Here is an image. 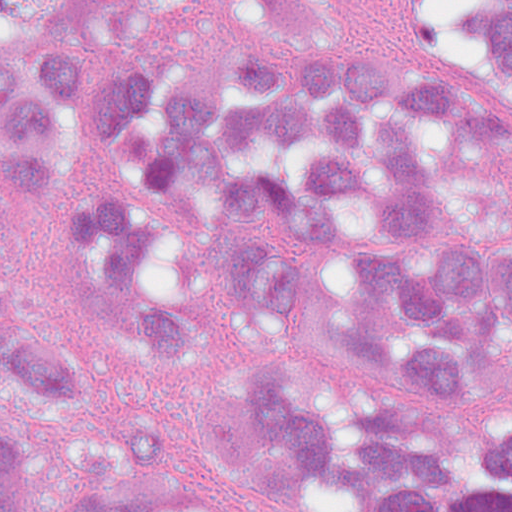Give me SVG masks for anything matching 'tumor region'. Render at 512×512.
Masks as SVG:
<instances>
[{
  "instance_id": "obj_1",
  "label": "tumor region",
  "mask_w": 512,
  "mask_h": 512,
  "mask_svg": "<svg viewBox=\"0 0 512 512\" xmlns=\"http://www.w3.org/2000/svg\"><path fill=\"white\" fill-rule=\"evenodd\" d=\"M150 20L194 0H88ZM441 86L390 61L305 69L264 49L211 86L156 61L92 73L78 0H0V163L40 191L87 119L130 165L71 198V262L155 363L283 342L351 387L333 419L277 353L234 358L173 472L105 414L78 350L14 284L0 223V512H288L316 470L380 512H512V419L451 429L372 401L344 367L427 384L512 360V239L497 189L461 171L512 129V0H395Z\"/></svg>"
}]
</instances>
